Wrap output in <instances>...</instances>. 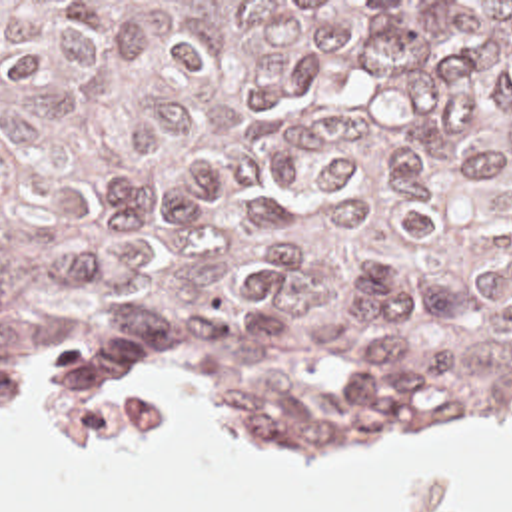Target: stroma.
<instances>
[{
  "label": "stroma",
  "mask_w": 512,
  "mask_h": 512,
  "mask_svg": "<svg viewBox=\"0 0 512 512\" xmlns=\"http://www.w3.org/2000/svg\"><path fill=\"white\" fill-rule=\"evenodd\" d=\"M0 2H94L118 28L124 16L128 14L132 2H512V0H0ZM180 357L188 361L194 369H198L208 383L218 393L224 409L230 413L231 421L239 425L245 431H251L267 441H313V439H337V437H353V435H369V433H381V431H327V429H315V427H285L269 423L265 413L261 411L259 403L241 393L230 379L224 375L216 351L212 333L206 325V321L160 365L128 379L122 383H116L112 387H106L86 399L70 401V403H0V411H44V409H56L66 405H108L122 395L130 393L136 387L150 385L172 371H176ZM493 421H509L512 427L511 415H473L443 423H431V425H415V427H445V425H481V423H493Z\"/></svg>",
  "instance_id": "35a3bbf8"
}]
</instances>
